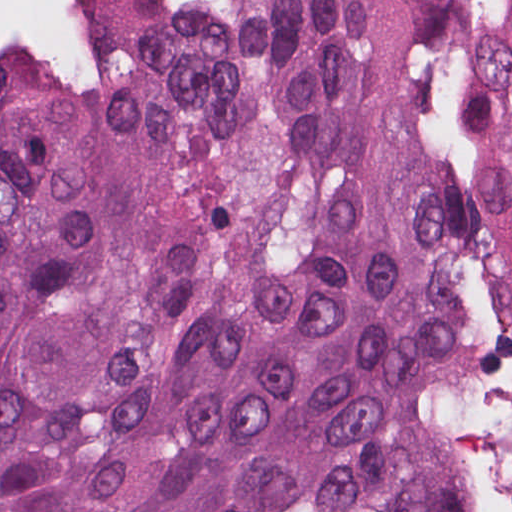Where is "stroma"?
Returning a JSON list of instances; mask_svg holds the SVG:
<instances>
[{"mask_svg":"<svg viewBox=\"0 0 512 512\" xmlns=\"http://www.w3.org/2000/svg\"><path fill=\"white\" fill-rule=\"evenodd\" d=\"M162 1L177 11H217L232 5L236 0ZM103 44L107 57L114 68V61L104 42ZM108 95L109 94L97 96H67L94 102ZM470 345L497 353L503 368L512 372L511 336L491 333H463L441 343L427 354L417 376V397L433 416L452 430H455L468 442L477 463L483 510L484 512H496L500 498V474L496 458L477 440L457 414L448 395L445 379V374L452 356ZM481 364L503 370L497 365ZM258 512L344 511L335 504L311 500L299 504L273 507Z\"/></svg>","mask_w":512,"mask_h":512,"instance_id":"stroma-1","label":"stroma"}]
</instances>
